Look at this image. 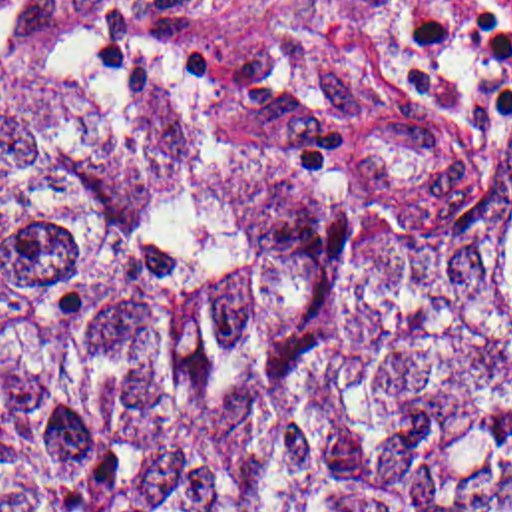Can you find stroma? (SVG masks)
Returning a JSON list of instances; mask_svg holds the SVG:
<instances>
[{
    "instance_id": "1",
    "label": "stroma",
    "mask_w": 512,
    "mask_h": 512,
    "mask_svg": "<svg viewBox=\"0 0 512 512\" xmlns=\"http://www.w3.org/2000/svg\"><path fill=\"white\" fill-rule=\"evenodd\" d=\"M412 0H240L207 43L348 143L414 161L467 147L512 117V95L481 125H447L398 79Z\"/></svg>"
}]
</instances>
